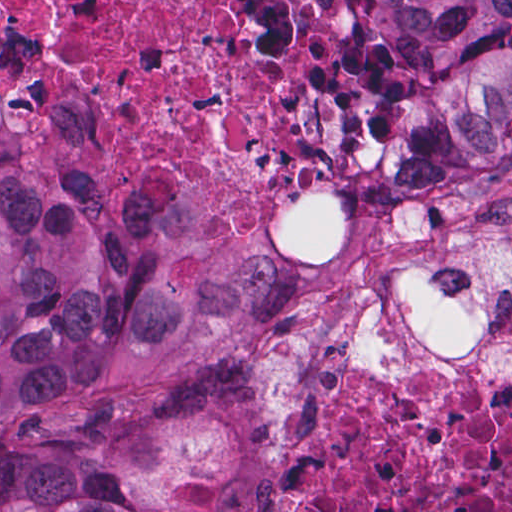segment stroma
Wrapping results in <instances>:
<instances>
[{
	"label": "stroma",
	"mask_w": 512,
	"mask_h": 512,
	"mask_svg": "<svg viewBox=\"0 0 512 512\" xmlns=\"http://www.w3.org/2000/svg\"><path fill=\"white\" fill-rule=\"evenodd\" d=\"M348 1L378 128L394 114V91L370 1L512 0ZM376 133L356 160L339 225L320 245L247 246L197 227L205 244L259 258L277 275L274 303L241 353L259 459L248 512L273 510L283 453L304 441L308 377L324 361L369 375L418 410L459 385L512 378V158L464 184L425 187V166H374Z\"/></svg>",
	"instance_id": "35a3bbf8"
}]
</instances>
